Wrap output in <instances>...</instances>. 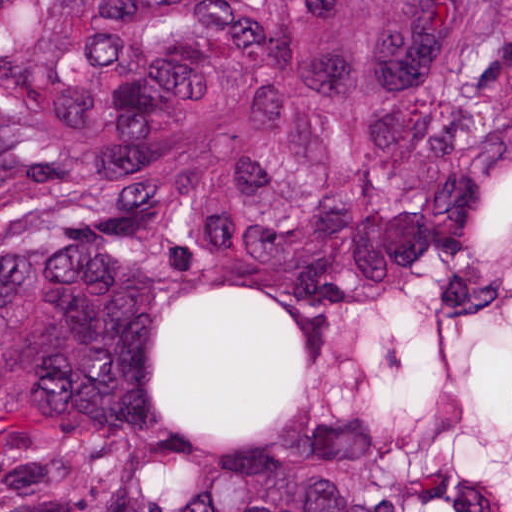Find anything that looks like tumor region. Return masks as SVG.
I'll use <instances>...</instances> for the list:
<instances>
[{
    "label": "tumor region",
    "mask_w": 512,
    "mask_h": 512,
    "mask_svg": "<svg viewBox=\"0 0 512 512\" xmlns=\"http://www.w3.org/2000/svg\"><path fill=\"white\" fill-rule=\"evenodd\" d=\"M0 512H512V0H0Z\"/></svg>",
    "instance_id": "1"
}]
</instances>
